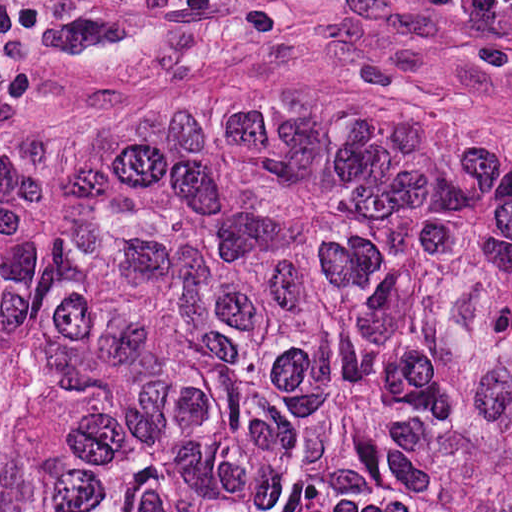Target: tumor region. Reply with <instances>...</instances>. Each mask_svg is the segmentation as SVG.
<instances>
[{
  "mask_svg": "<svg viewBox=\"0 0 512 512\" xmlns=\"http://www.w3.org/2000/svg\"><path fill=\"white\" fill-rule=\"evenodd\" d=\"M0 512H512V132L186 95L0 135Z\"/></svg>",
  "mask_w": 512,
  "mask_h": 512,
  "instance_id": "tumor-region-1",
  "label": "tumor region"
}]
</instances>
